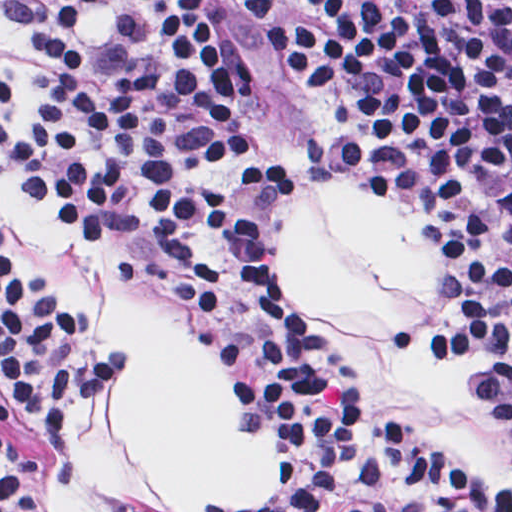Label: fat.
Wrapping results in <instances>:
<instances>
[{
    "label": "fat",
    "instance_id": "fat-1",
    "mask_svg": "<svg viewBox=\"0 0 512 512\" xmlns=\"http://www.w3.org/2000/svg\"><path fill=\"white\" fill-rule=\"evenodd\" d=\"M76 28L86 41H104L111 2L87 4ZM268 239L280 277L360 360L377 406L435 442L472 480H512V443L481 412V372L399 344L389 326L433 320L448 283L457 292L461 268L432 235L358 180L316 184ZM94 328L127 358L133 435L175 512L243 496L277 472V427L234 431L224 357L178 340L138 295L116 287Z\"/></svg>",
    "mask_w": 512,
    "mask_h": 512
}]
</instances>
